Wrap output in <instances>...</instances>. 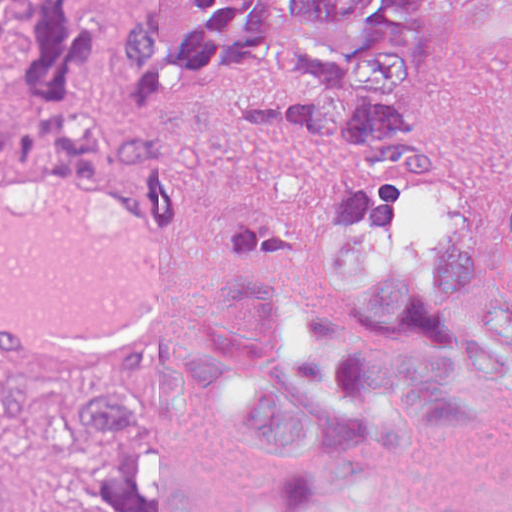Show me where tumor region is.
Returning a JSON list of instances; mask_svg holds the SVG:
<instances>
[{"label": "tumor region", "instance_id": "obj_1", "mask_svg": "<svg viewBox=\"0 0 512 512\" xmlns=\"http://www.w3.org/2000/svg\"><path fill=\"white\" fill-rule=\"evenodd\" d=\"M437 0H128L113 92L87 81L103 48L93 0H0V169L103 173V130L182 127L230 101L247 125L343 152L361 178L438 181L423 117ZM453 42L512 56V0H453ZM270 80L290 98H235ZM184 364L163 348L99 362L63 386L0 376V461L81 512H184ZM0 512L16 505L0 493Z\"/></svg>", "mask_w": 512, "mask_h": 512}]
</instances>
